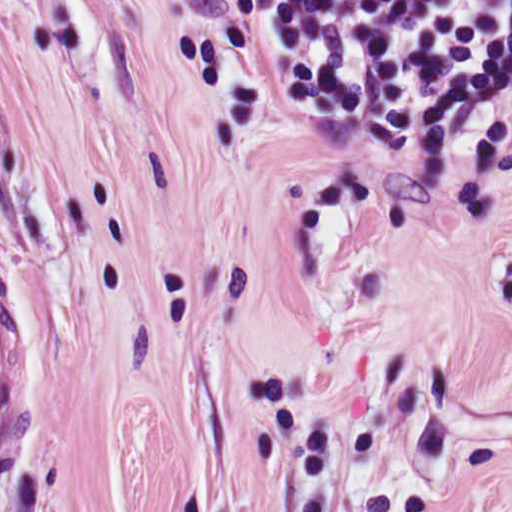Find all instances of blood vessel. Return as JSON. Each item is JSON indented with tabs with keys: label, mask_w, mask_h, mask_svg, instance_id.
<instances>
[{
	"label": "blood vessel",
	"mask_w": 512,
	"mask_h": 512,
	"mask_svg": "<svg viewBox=\"0 0 512 512\" xmlns=\"http://www.w3.org/2000/svg\"><path fill=\"white\" fill-rule=\"evenodd\" d=\"M32 397L31 340L0 300V460L28 425Z\"/></svg>",
	"instance_id": "obj_1"
}]
</instances>
